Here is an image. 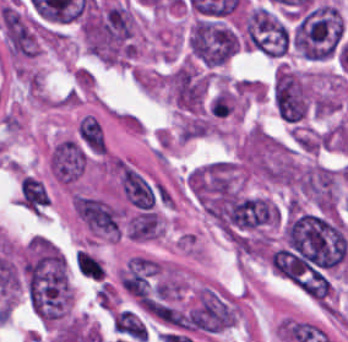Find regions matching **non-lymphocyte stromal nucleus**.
<instances>
[{
	"mask_svg": "<svg viewBox=\"0 0 348 342\" xmlns=\"http://www.w3.org/2000/svg\"><path fill=\"white\" fill-rule=\"evenodd\" d=\"M113 329L115 332L139 341H147L148 334L143 322L130 310H123L116 314L113 320Z\"/></svg>",
	"mask_w": 348,
	"mask_h": 342,
	"instance_id": "7",
	"label": "non-lymphocyte stromal nucleus"
},
{
	"mask_svg": "<svg viewBox=\"0 0 348 342\" xmlns=\"http://www.w3.org/2000/svg\"><path fill=\"white\" fill-rule=\"evenodd\" d=\"M77 137L83 147L91 154H105L107 150L106 135L96 117L86 114L81 119Z\"/></svg>",
	"mask_w": 348,
	"mask_h": 342,
	"instance_id": "5",
	"label": "non-lymphocyte stromal nucleus"
},
{
	"mask_svg": "<svg viewBox=\"0 0 348 342\" xmlns=\"http://www.w3.org/2000/svg\"><path fill=\"white\" fill-rule=\"evenodd\" d=\"M72 205L75 215L91 232L119 239V209L97 198L75 193Z\"/></svg>",
	"mask_w": 348,
	"mask_h": 342,
	"instance_id": "1",
	"label": "non-lymphocyte stromal nucleus"
},
{
	"mask_svg": "<svg viewBox=\"0 0 348 342\" xmlns=\"http://www.w3.org/2000/svg\"><path fill=\"white\" fill-rule=\"evenodd\" d=\"M87 154L82 144L74 137L54 143L48 166L56 181L65 185H74L84 174Z\"/></svg>",
	"mask_w": 348,
	"mask_h": 342,
	"instance_id": "2",
	"label": "non-lymphocyte stromal nucleus"
},
{
	"mask_svg": "<svg viewBox=\"0 0 348 342\" xmlns=\"http://www.w3.org/2000/svg\"><path fill=\"white\" fill-rule=\"evenodd\" d=\"M117 168L124 198L134 207L143 210L154 208L156 195L152 186L131 165L118 159Z\"/></svg>",
	"mask_w": 348,
	"mask_h": 342,
	"instance_id": "3",
	"label": "non-lymphocyte stromal nucleus"
},
{
	"mask_svg": "<svg viewBox=\"0 0 348 342\" xmlns=\"http://www.w3.org/2000/svg\"><path fill=\"white\" fill-rule=\"evenodd\" d=\"M160 231V218L151 212L139 213L127 224V235L133 240L156 239Z\"/></svg>",
	"mask_w": 348,
	"mask_h": 342,
	"instance_id": "6",
	"label": "non-lymphocyte stromal nucleus"
},
{
	"mask_svg": "<svg viewBox=\"0 0 348 342\" xmlns=\"http://www.w3.org/2000/svg\"><path fill=\"white\" fill-rule=\"evenodd\" d=\"M16 199L31 213L42 214L48 207L46 187L31 175L20 177Z\"/></svg>",
	"mask_w": 348,
	"mask_h": 342,
	"instance_id": "4",
	"label": "non-lymphocyte stromal nucleus"
}]
</instances>
